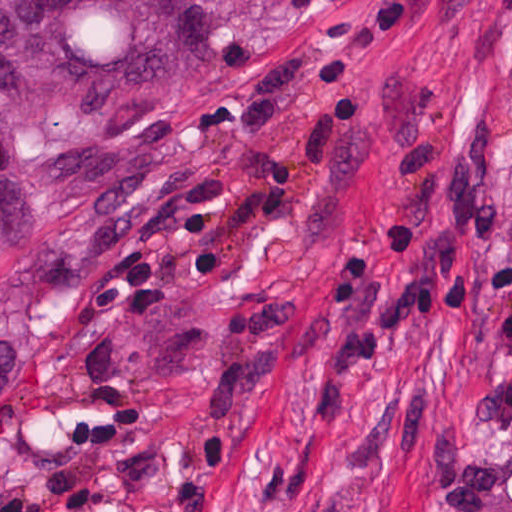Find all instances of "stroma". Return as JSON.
<instances>
[{
	"label": "stroma",
	"instance_id": "1",
	"mask_svg": "<svg viewBox=\"0 0 512 512\" xmlns=\"http://www.w3.org/2000/svg\"><path fill=\"white\" fill-rule=\"evenodd\" d=\"M159 112L29 152L0 512H512V0H185Z\"/></svg>",
	"mask_w": 512,
	"mask_h": 512
}]
</instances>
